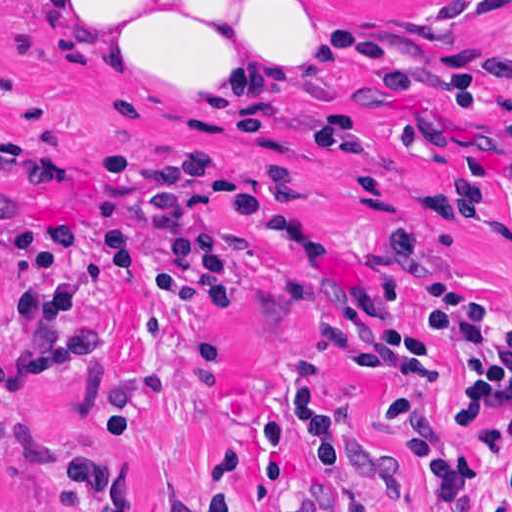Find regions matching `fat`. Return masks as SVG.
I'll return each mask as SVG.
<instances>
[{"label":"fat","mask_w":512,"mask_h":512,"mask_svg":"<svg viewBox=\"0 0 512 512\" xmlns=\"http://www.w3.org/2000/svg\"><path fill=\"white\" fill-rule=\"evenodd\" d=\"M40 44L147 98L272 114L313 86L302 0H40Z\"/></svg>","instance_id":"1"}]
</instances>
